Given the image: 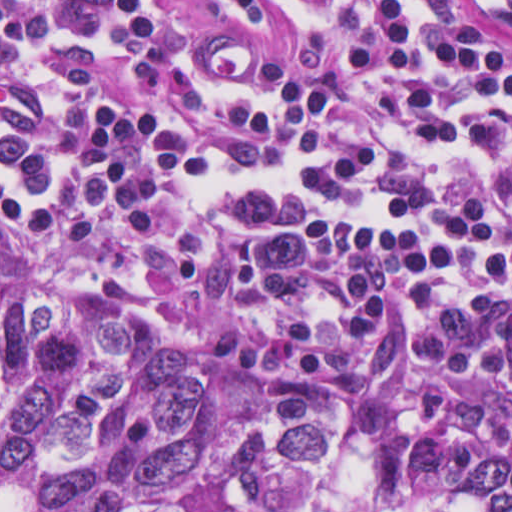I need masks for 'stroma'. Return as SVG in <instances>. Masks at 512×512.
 <instances>
[{"label":"stroma","mask_w":512,"mask_h":512,"mask_svg":"<svg viewBox=\"0 0 512 512\" xmlns=\"http://www.w3.org/2000/svg\"><path fill=\"white\" fill-rule=\"evenodd\" d=\"M170 1L189 20L214 37L233 33L244 35L273 67L287 65L294 57L288 34L274 18L256 22L245 19L232 0ZM461 1L476 30L497 47L512 51V18L486 15L473 0ZM0 280L24 284L42 295L81 307L122 302L139 316L133 302L125 295L87 283L43 278L3 258H0ZM140 320L156 339L175 349L195 353ZM251 369L299 386H324L339 405L345 427L339 446L316 487L292 492H227L229 512H351L382 467L403 450L385 444L361 427L339 397L318 378L291 369Z\"/></svg>","instance_id":"35a3bbf8"}]
</instances>
